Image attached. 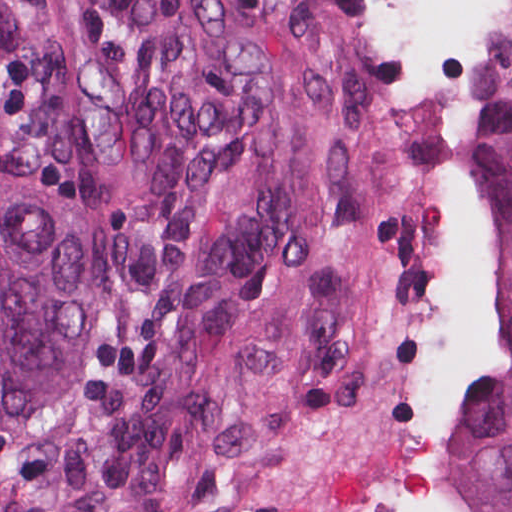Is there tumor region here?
Wrapping results in <instances>:
<instances>
[{"instance_id":"e687c5a6","label":"tumor region","mask_w":512,"mask_h":512,"mask_svg":"<svg viewBox=\"0 0 512 512\" xmlns=\"http://www.w3.org/2000/svg\"><path fill=\"white\" fill-rule=\"evenodd\" d=\"M499 368L444 512H512V51L469 155ZM275 195L234 45L117 0H0V512H210Z\"/></svg>"}]
</instances>
